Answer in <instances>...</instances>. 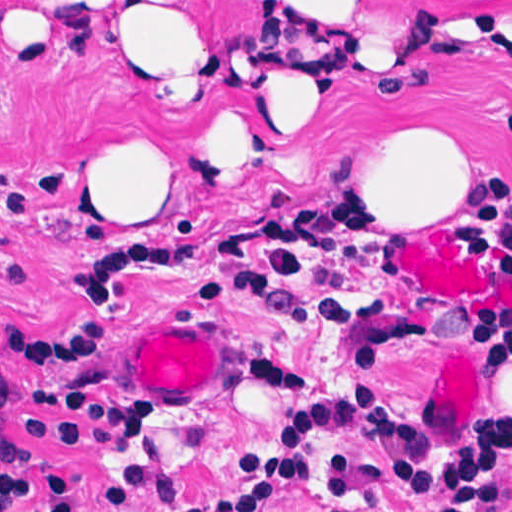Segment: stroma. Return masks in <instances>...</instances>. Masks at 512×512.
Instances as JSON below:
<instances>
[{"instance_id": "obj_1", "label": "stroma", "mask_w": 512, "mask_h": 512, "mask_svg": "<svg viewBox=\"0 0 512 512\" xmlns=\"http://www.w3.org/2000/svg\"><path fill=\"white\" fill-rule=\"evenodd\" d=\"M179 21L194 88L133 67L114 28ZM298 45L250 0H0V308L30 312L72 251L132 229L220 230L205 245L121 242L89 260L78 300L135 280L188 287L185 306L112 335L110 387L141 440L120 454L63 446L0 406V429L37 467L70 470L83 512H223L263 489L273 512H424L395 492L414 435L471 459L475 435L512 411V308L440 303L401 272L414 232L444 229L480 258L449 209L329 200L357 183V126L410 101L447 107L475 141L478 173L512 176V0H339L314 46L338 62L309 77L325 111L305 136L201 180L184 147L249 71ZM126 150L164 175L168 210H120ZM512 235V224L507 227ZM481 259V258H480ZM241 322L264 334L246 369ZM32 370L0 351V383ZM512 505V447L507 454Z\"/></svg>"}]
</instances>
